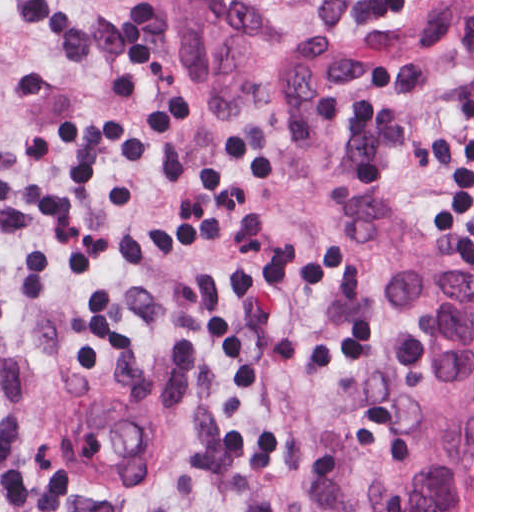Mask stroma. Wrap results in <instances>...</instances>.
<instances>
[{
  "label": "stroma",
  "instance_id": "obj_1",
  "mask_svg": "<svg viewBox=\"0 0 512 512\" xmlns=\"http://www.w3.org/2000/svg\"><path fill=\"white\" fill-rule=\"evenodd\" d=\"M282 110L213 114L108 0H0V512H306L338 434L384 479L405 449L390 343L317 225L360 191L472 261L473 35L340 55L368 0H240ZM186 427L178 477L112 498L48 458L69 396Z\"/></svg>",
  "mask_w": 512,
  "mask_h": 512
}]
</instances>
